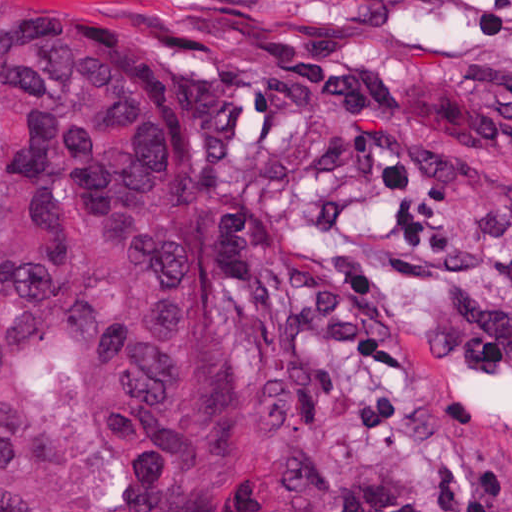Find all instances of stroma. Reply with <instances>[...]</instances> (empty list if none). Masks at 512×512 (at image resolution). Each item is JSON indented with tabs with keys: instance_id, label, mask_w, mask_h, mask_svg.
<instances>
[{
	"instance_id": "35a3bbf8",
	"label": "stroma",
	"mask_w": 512,
	"mask_h": 512,
	"mask_svg": "<svg viewBox=\"0 0 512 512\" xmlns=\"http://www.w3.org/2000/svg\"><path fill=\"white\" fill-rule=\"evenodd\" d=\"M29 1L182 125L256 512H512V0Z\"/></svg>"
}]
</instances>
